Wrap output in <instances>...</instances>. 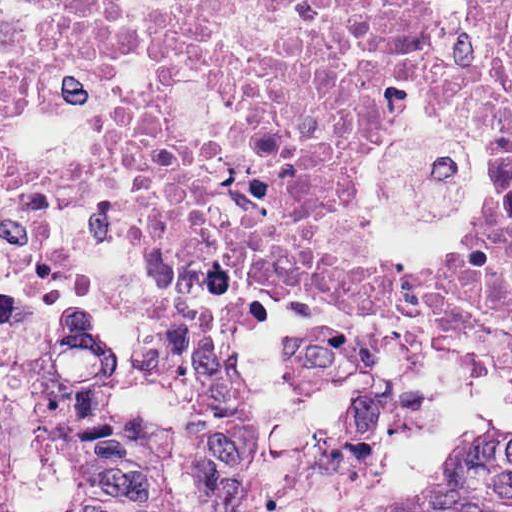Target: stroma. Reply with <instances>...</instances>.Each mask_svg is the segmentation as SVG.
<instances>
[{
	"label": "stroma",
	"mask_w": 512,
	"mask_h": 512,
	"mask_svg": "<svg viewBox=\"0 0 512 512\" xmlns=\"http://www.w3.org/2000/svg\"><path fill=\"white\" fill-rule=\"evenodd\" d=\"M457 101L405 71L395 125L373 140L365 159V220L377 255L402 281L467 253L487 196L483 129L443 113ZM80 309H103L118 325L129 356V403L285 333V322L247 299L159 281L94 220L61 239L41 279L0 288V371L23 363L33 334Z\"/></svg>",
	"instance_id": "1"
}]
</instances>
